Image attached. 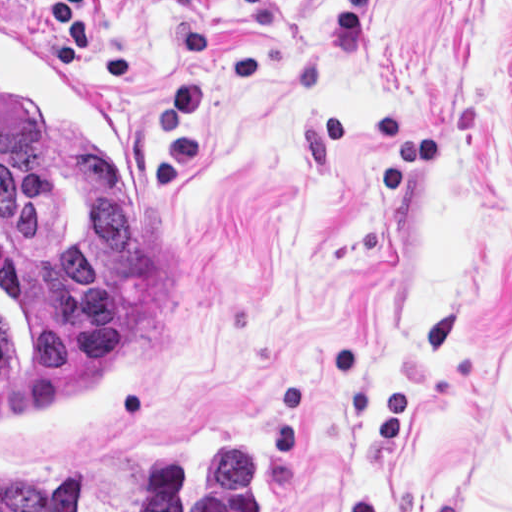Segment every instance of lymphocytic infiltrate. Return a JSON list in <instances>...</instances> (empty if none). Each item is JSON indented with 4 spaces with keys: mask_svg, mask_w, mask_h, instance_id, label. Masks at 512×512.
<instances>
[{
    "mask_svg": "<svg viewBox=\"0 0 512 512\" xmlns=\"http://www.w3.org/2000/svg\"><path fill=\"white\" fill-rule=\"evenodd\" d=\"M52 22L61 54L89 82L120 83L129 76V62L123 51L87 33L85 0H52Z\"/></svg>",
    "mask_w": 512,
    "mask_h": 512,
    "instance_id": "lymphocytic-infiltrate-1",
    "label": "lymphocytic infiltrate"
}]
</instances>
